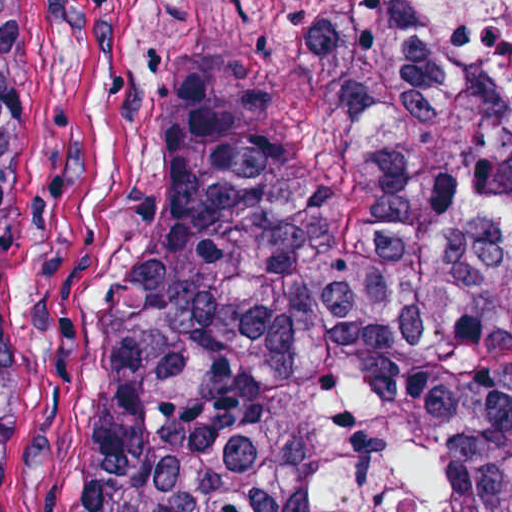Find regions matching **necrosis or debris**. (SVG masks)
Here are the masks:
<instances>
[{"label": "necrosis or debris", "mask_w": 512, "mask_h": 512, "mask_svg": "<svg viewBox=\"0 0 512 512\" xmlns=\"http://www.w3.org/2000/svg\"><path fill=\"white\" fill-rule=\"evenodd\" d=\"M430 50L512 93V0H397ZM323 512H439L432 423L375 367L317 389Z\"/></svg>", "instance_id": "1"}]
</instances>
